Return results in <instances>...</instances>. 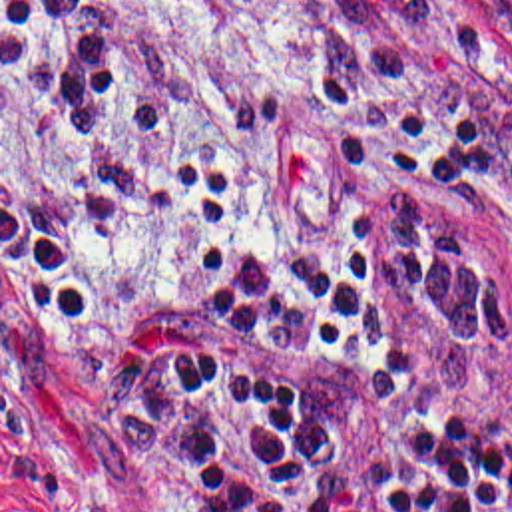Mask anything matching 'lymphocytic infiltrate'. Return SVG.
Here are the masks:
<instances>
[{"instance_id":"1","label":"lymphocytic infiltrate","mask_w":512,"mask_h":512,"mask_svg":"<svg viewBox=\"0 0 512 512\" xmlns=\"http://www.w3.org/2000/svg\"><path fill=\"white\" fill-rule=\"evenodd\" d=\"M4 36L80 137H145L189 97L96 58L82 0H2ZM341 253L231 245L233 173L183 159L167 207L195 277L187 318L106 311L62 237L2 197V263L62 326L173 512H512V289L440 221L480 141L307 76Z\"/></svg>"}]
</instances>
